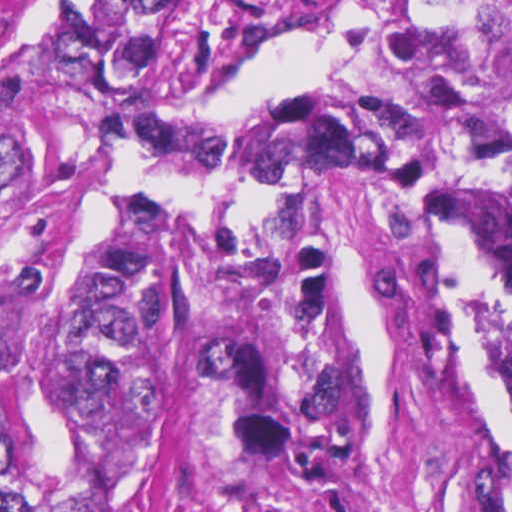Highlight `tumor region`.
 <instances>
[{
  "label": "tumor region",
  "instance_id": "1",
  "mask_svg": "<svg viewBox=\"0 0 512 512\" xmlns=\"http://www.w3.org/2000/svg\"><path fill=\"white\" fill-rule=\"evenodd\" d=\"M303 0H1V160L107 145L188 182L318 164L388 207L452 173L512 216V0H365L352 69L280 101L180 112ZM464 326L449 437L479 512H512V243L453 254ZM39 267L1 268V512H118L180 328L235 325L186 366L234 448L316 479L352 467L359 369L332 260L292 245L186 276L169 210L126 202L68 298L21 319Z\"/></svg>",
  "mask_w": 512,
  "mask_h": 512
}]
</instances>
